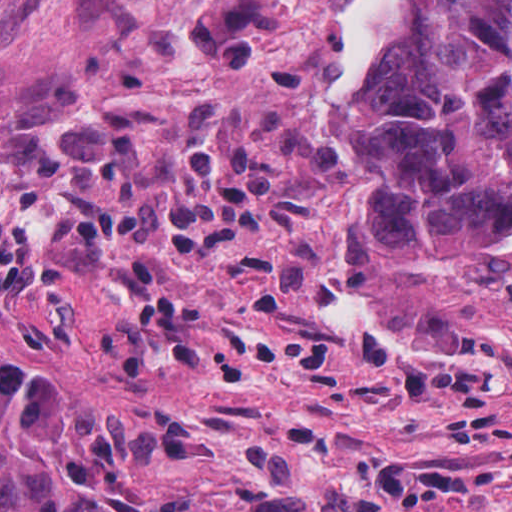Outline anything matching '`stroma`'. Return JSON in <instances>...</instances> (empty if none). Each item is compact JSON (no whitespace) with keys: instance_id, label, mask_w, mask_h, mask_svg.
<instances>
[{"instance_id":"1","label":"stroma","mask_w":512,"mask_h":512,"mask_svg":"<svg viewBox=\"0 0 512 512\" xmlns=\"http://www.w3.org/2000/svg\"><path fill=\"white\" fill-rule=\"evenodd\" d=\"M396 1L0 0V512H512V240L342 247Z\"/></svg>"}]
</instances>
